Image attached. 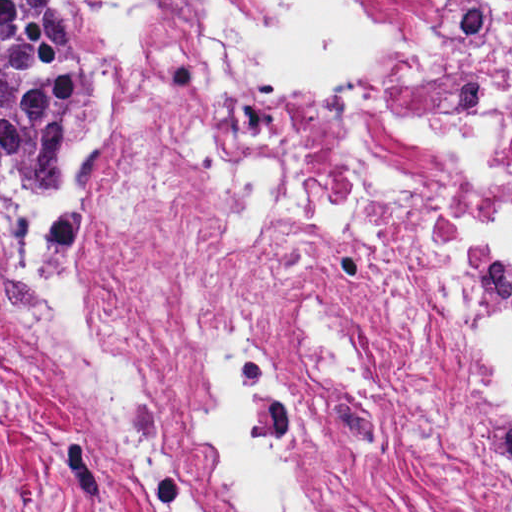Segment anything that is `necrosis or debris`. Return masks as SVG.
<instances>
[{"mask_svg":"<svg viewBox=\"0 0 512 512\" xmlns=\"http://www.w3.org/2000/svg\"><path fill=\"white\" fill-rule=\"evenodd\" d=\"M143 121L90 230L0 196V328L143 512H512V0H87Z\"/></svg>","mask_w":512,"mask_h":512,"instance_id":"necrosis-or-debris-1","label":"necrosis or debris"}]
</instances>
